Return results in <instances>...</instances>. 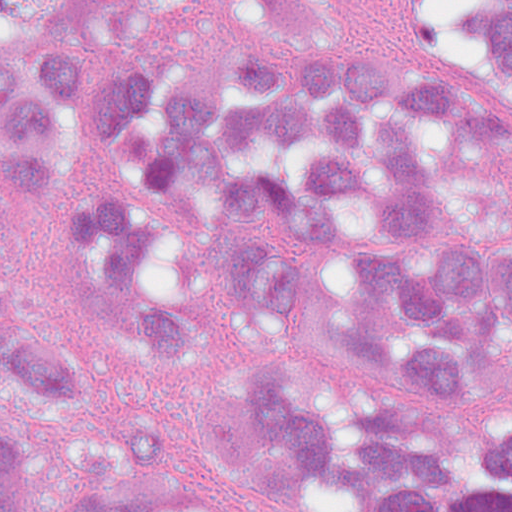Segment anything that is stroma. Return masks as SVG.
<instances>
[{"mask_svg": "<svg viewBox=\"0 0 512 512\" xmlns=\"http://www.w3.org/2000/svg\"><path fill=\"white\" fill-rule=\"evenodd\" d=\"M80 33L92 73L142 58L216 86L235 81L262 50L289 53L305 69L345 61H390L407 78L441 86L406 34L395 0H194L150 20H117L78 0ZM84 135L59 178L40 191L7 181L0 163V223L15 287L29 310L68 338L106 415L135 431L144 462L173 472L190 453L202 421L226 398L234 358L277 353L316 385L333 419L351 409V387L323 354L283 342L242 345L222 357L179 367L155 363L134 320L98 298L71 262L63 219L71 198H114L130 188V165ZM502 197L512 239V129L462 169ZM353 389L409 416L451 429H499L512 419V360L485 363L469 380L427 384L367 363L344 367ZM288 512H380L356 490L319 472Z\"/></svg>", "mask_w": 512, "mask_h": 512, "instance_id": "stroma-1", "label": "stroma"}]
</instances>
